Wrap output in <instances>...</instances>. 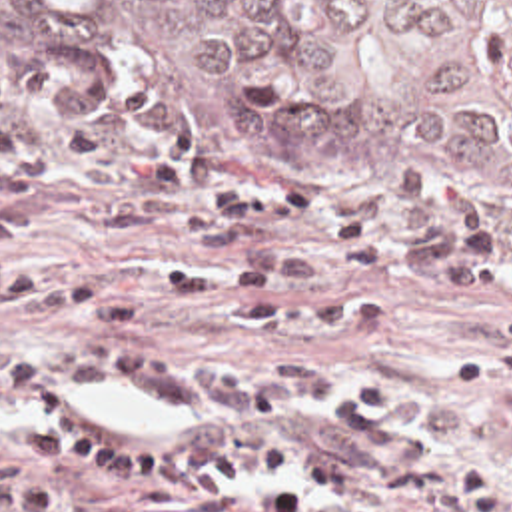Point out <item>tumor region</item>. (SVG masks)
<instances>
[{
  "label": "tumor region",
  "mask_w": 512,
  "mask_h": 512,
  "mask_svg": "<svg viewBox=\"0 0 512 512\" xmlns=\"http://www.w3.org/2000/svg\"><path fill=\"white\" fill-rule=\"evenodd\" d=\"M0 55L224 156L512 184V0H0Z\"/></svg>",
  "instance_id": "1"
}]
</instances>
